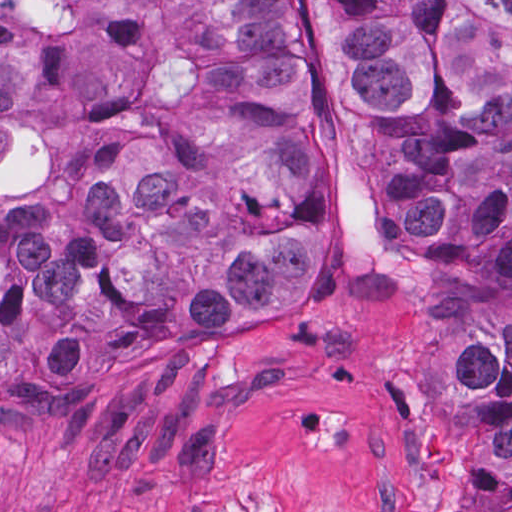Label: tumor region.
<instances>
[{"mask_svg": "<svg viewBox=\"0 0 512 512\" xmlns=\"http://www.w3.org/2000/svg\"><path fill=\"white\" fill-rule=\"evenodd\" d=\"M455 512H512V0H321ZM280 0H0V405L305 317Z\"/></svg>", "mask_w": 512, "mask_h": 512, "instance_id": "tumor-region-1", "label": "tumor region"}]
</instances>
